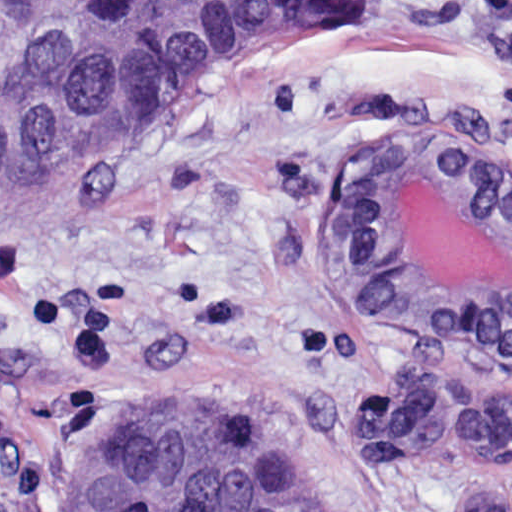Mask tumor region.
Here are the masks:
<instances>
[{
	"instance_id": "obj_1",
	"label": "tumor region",
	"mask_w": 512,
	"mask_h": 512,
	"mask_svg": "<svg viewBox=\"0 0 512 512\" xmlns=\"http://www.w3.org/2000/svg\"><path fill=\"white\" fill-rule=\"evenodd\" d=\"M365 0H0V205L107 166L272 52L361 27ZM380 460L512 458V403L428 387L328 416ZM70 479L62 512H323L287 443L203 396H134ZM454 512H505L465 496Z\"/></svg>"
}]
</instances>
